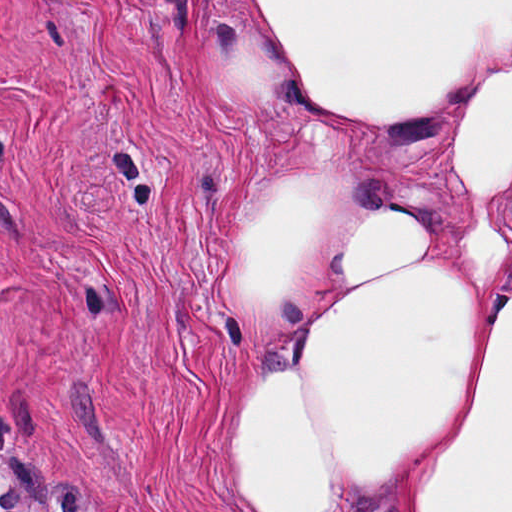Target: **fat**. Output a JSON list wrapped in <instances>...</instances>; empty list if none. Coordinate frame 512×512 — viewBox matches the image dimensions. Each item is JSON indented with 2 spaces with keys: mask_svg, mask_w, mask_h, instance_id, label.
Here are the masks:
<instances>
[{
  "mask_svg": "<svg viewBox=\"0 0 512 512\" xmlns=\"http://www.w3.org/2000/svg\"><path fill=\"white\" fill-rule=\"evenodd\" d=\"M232 2L340 114L341 151L272 172L246 206L234 290L275 322L312 259L416 142L455 126L468 203L369 208L258 383L250 512H512V284L467 270L512 194V0Z\"/></svg>",
  "mask_w": 512,
  "mask_h": 512,
  "instance_id": "fat-1",
  "label": "fat"
}]
</instances>
